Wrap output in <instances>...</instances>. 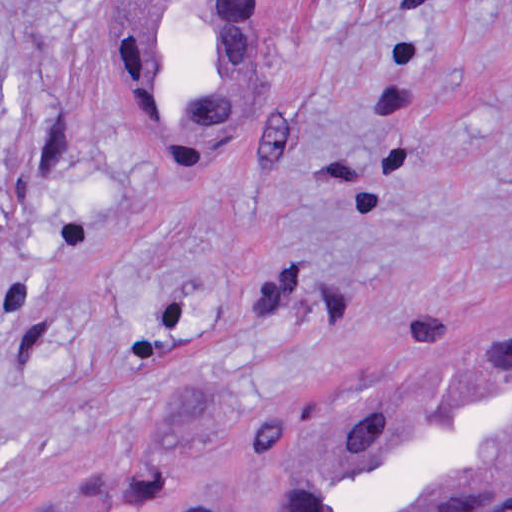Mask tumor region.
Returning <instances> with one entry per match:
<instances>
[{"label": "tumor region", "instance_id": "tumor-region-1", "mask_svg": "<svg viewBox=\"0 0 512 512\" xmlns=\"http://www.w3.org/2000/svg\"><path fill=\"white\" fill-rule=\"evenodd\" d=\"M27 72L28 62L0 60V159L15 130ZM38 512L223 511L184 473L82 471ZM493 512H512V500Z\"/></svg>", "mask_w": 512, "mask_h": 512}]
</instances>
